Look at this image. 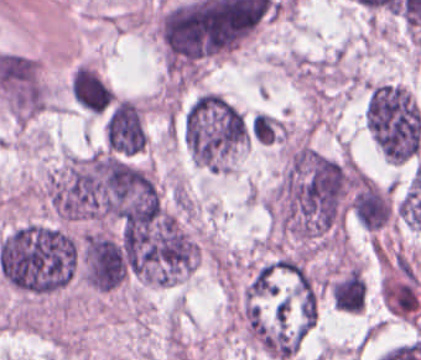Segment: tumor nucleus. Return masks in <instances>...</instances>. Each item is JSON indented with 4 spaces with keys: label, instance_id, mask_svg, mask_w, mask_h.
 <instances>
[{
    "label": "tumor nucleus",
    "instance_id": "obj_1",
    "mask_svg": "<svg viewBox=\"0 0 421 360\" xmlns=\"http://www.w3.org/2000/svg\"><path fill=\"white\" fill-rule=\"evenodd\" d=\"M181 135L199 166L234 171L250 138L249 120L223 93L202 91L183 109Z\"/></svg>",
    "mask_w": 421,
    "mask_h": 360
},
{
    "label": "tumor nucleus",
    "instance_id": "obj_2",
    "mask_svg": "<svg viewBox=\"0 0 421 360\" xmlns=\"http://www.w3.org/2000/svg\"><path fill=\"white\" fill-rule=\"evenodd\" d=\"M364 126L379 150H419L421 110L403 86H371L363 112Z\"/></svg>",
    "mask_w": 421,
    "mask_h": 360
},
{
    "label": "tumor nucleus",
    "instance_id": "obj_3",
    "mask_svg": "<svg viewBox=\"0 0 421 360\" xmlns=\"http://www.w3.org/2000/svg\"><path fill=\"white\" fill-rule=\"evenodd\" d=\"M70 98L80 109L101 114L114 101L113 92L95 62H75L68 72Z\"/></svg>",
    "mask_w": 421,
    "mask_h": 360
}]
</instances>
